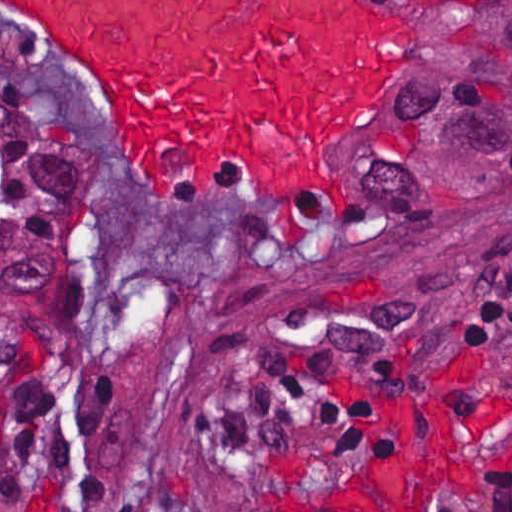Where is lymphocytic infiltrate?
<instances>
[{"label":"lymphocytic infiltrate","mask_w":512,"mask_h":512,"mask_svg":"<svg viewBox=\"0 0 512 512\" xmlns=\"http://www.w3.org/2000/svg\"><path fill=\"white\" fill-rule=\"evenodd\" d=\"M498 325L512 328V260L459 316L463 335ZM262 394L271 411L314 423L361 457H384L396 446L402 398L380 348L318 336L262 382ZM119 430L120 395L96 377L0 403V486L54 477L83 500H102V461ZM472 512H512V452L490 463Z\"/></svg>","instance_id":"f902f5d3"}]
</instances>
